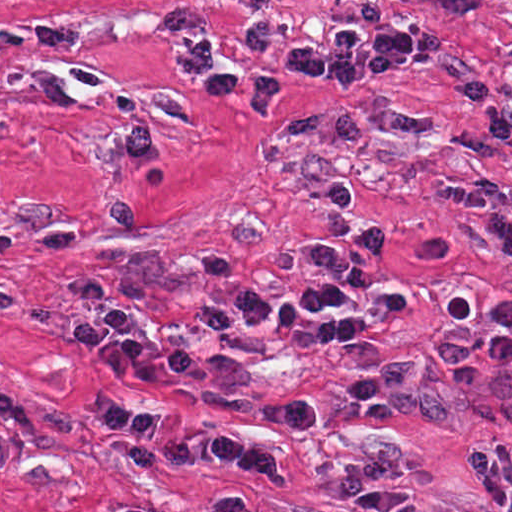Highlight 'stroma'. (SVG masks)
<instances>
[{"mask_svg": "<svg viewBox=\"0 0 512 512\" xmlns=\"http://www.w3.org/2000/svg\"><path fill=\"white\" fill-rule=\"evenodd\" d=\"M428 26L436 59L348 89L295 79L268 116L217 101L181 72L192 39L214 61L266 64L326 27ZM512 193V0H0V512H358L328 499L341 470L498 512L467 471L474 443H512V373L465 400L431 364L437 339L497 331L512 267L439 187ZM374 228L365 337L320 343L311 320L237 333L211 354L249 360L235 387L191 373L130 384L165 428L240 434L277 454L279 481L210 461L146 466L89 409L108 372L75 332L116 306L144 337L187 342L193 312L228 296H295L302 255ZM416 362L457 420L388 409L371 424L320 404L319 424L255 414Z\"/></svg>", "mask_w": 512, "mask_h": 512, "instance_id": "35a3bbf8", "label": "stroma"}]
</instances>
